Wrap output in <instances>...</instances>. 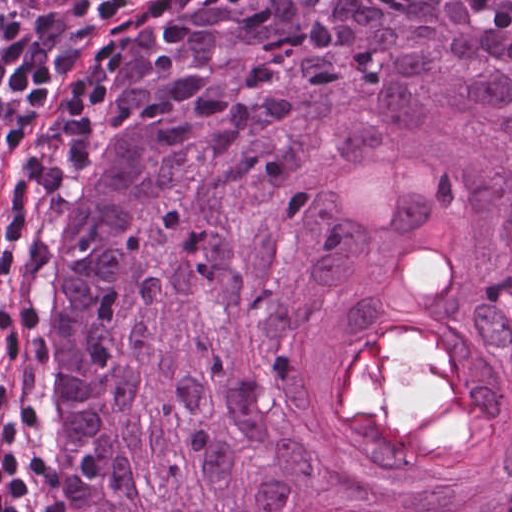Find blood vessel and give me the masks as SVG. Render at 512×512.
Masks as SVG:
<instances>
[{"label": "blood vessel", "instance_id": "obj_1", "mask_svg": "<svg viewBox=\"0 0 512 512\" xmlns=\"http://www.w3.org/2000/svg\"><path fill=\"white\" fill-rule=\"evenodd\" d=\"M91 0H8L19 12H46L61 7L78 6Z\"/></svg>", "mask_w": 512, "mask_h": 512}]
</instances>
